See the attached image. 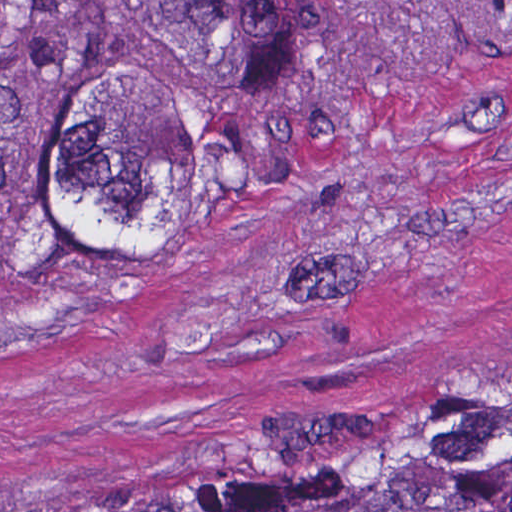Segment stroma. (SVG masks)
<instances>
[{
  "instance_id": "stroma-1",
  "label": "stroma",
  "mask_w": 512,
  "mask_h": 512,
  "mask_svg": "<svg viewBox=\"0 0 512 512\" xmlns=\"http://www.w3.org/2000/svg\"><path fill=\"white\" fill-rule=\"evenodd\" d=\"M337 31L309 186L0 291V512L204 508L512 393V0H337Z\"/></svg>"
}]
</instances>
